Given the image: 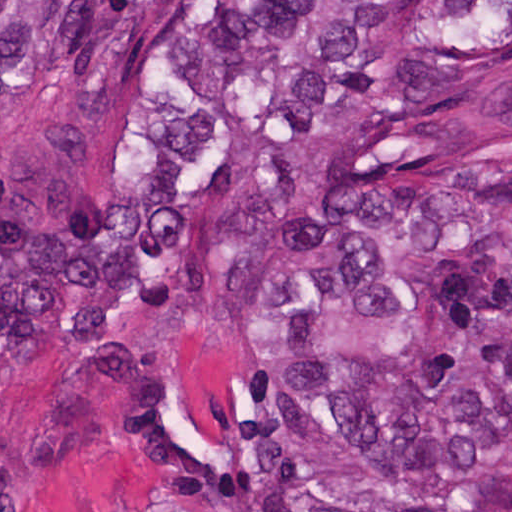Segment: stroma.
Wrapping results in <instances>:
<instances>
[{
	"label": "stroma",
	"instance_id": "stroma-1",
	"mask_svg": "<svg viewBox=\"0 0 512 512\" xmlns=\"http://www.w3.org/2000/svg\"><path fill=\"white\" fill-rule=\"evenodd\" d=\"M182 1L135 74L58 75L0 92V210L61 167L135 162L167 119L159 88L167 49L225 1H331L347 16L372 1L512 0H0ZM314 149L311 147L310 154ZM305 184L262 236L227 248L206 305L151 321L138 341L159 361L204 467L161 424L124 409L111 387L96 418L69 391L75 346L63 332L0 349V512H205L243 489L257 414L286 365L381 352L396 320L381 310L316 314L275 324L255 317L248 275L287 237L309 200Z\"/></svg>",
	"mask_w": 512,
	"mask_h": 512
}]
</instances>
